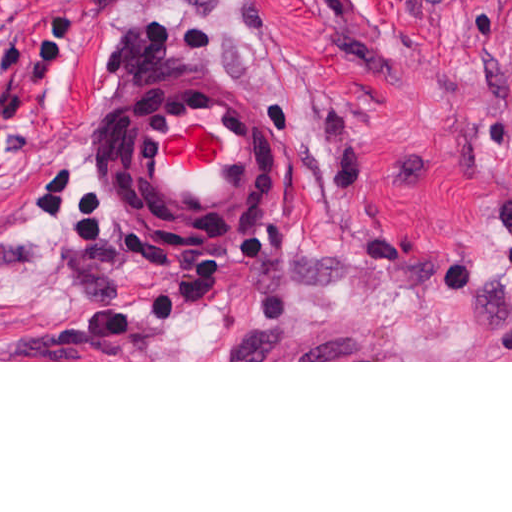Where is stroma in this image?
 <instances>
[{"label": "stroma", "mask_w": 512, "mask_h": 512, "mask_svg": "<svg viewBox=\"0 0 512 512\" xmlns=\"http://www.w3.org/2000/svg\"><path fill=\"white\" fill-rule=\"evenodd\" d=\"M233 65L278 176L205 262L120 156ZM0 362H512V0H0Z\"/></svg>", "instance_id": "stroma-1"}]
</instances>
